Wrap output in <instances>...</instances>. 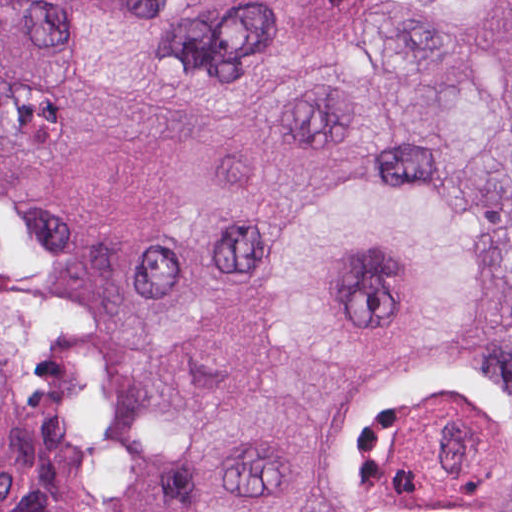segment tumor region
I'll return each instance as SVG.
<instances>
[{
  "mask_svg": "<svg viewBox=\"0 0 512 512\" xmlns=\"http://www.w3.org/2000/svg\"><path fill=\"white\" fill-rule=\"evenodd\" d=\"M257 1L0 0V512H512V0Z\"/></svg>",
  "mask_w": 512,
  "mask_h": 512,
  "instance_id": "e687c5a6",
  "label": "tumor region"
}]
</instances>
